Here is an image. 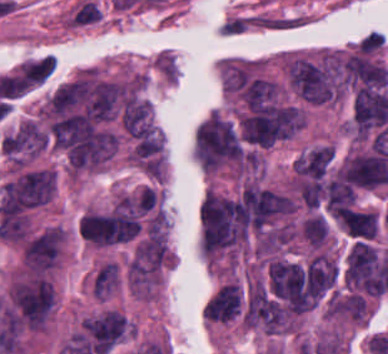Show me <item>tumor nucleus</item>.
<instances>
[{"mask_svg": "<svg viewBox=\"0 0 388 354\" xmlns=\"http://www.w3.org/2000/svg\"><path fill=\"white\" fill-rule=\"evenodd\" d=\"M247 237L238 197L211 192L200 207L201 250L217 255L240 247Z\"/></svg>", "mask_w": 388, "mask_h": 354, "instance_id": "obj_1", "label": "tumor nucleus"}, {"mask_svg": "<svg viewBox=\"0 0 388 354\" xmlns=\"http://www.w3.org/2000/svg\"><path fill=\"white\" fill-rule=\"evenodd\" d=\"M194 154L204 169L214 171L246 158L232 124L215 112L197 126Z\"/></svg>", "mask_w": 388, "mask_h": 354, "instance_id": "obj_2", "label": "tumor nucleus"}, {"mask_svg": "<svg viewBox=\"0 0 388 354\" xmlns=\"http://www.w3.org/2000/svg\"><path fill=\"white\" fill-rule=\"evenodd\" d=\"M12 303L25 324L34 330H42L53 309V286L42 276L17 282L13 288Z\"/></svg>", "mask_w": 388, "mask_h": 354, "instance_id": "obj_3", "label": "tumor nucleus"}, {"mask_svg": "<svg viewBox=\"0 0 388 354\" xmlns=\"http://www.w3.org/2000/svg\"><path fill=\"white\" fill-rule=\"evenodd\" d=\"M293 209L286 193L270 188L247 186L240 198L242 220L250 228L263 230Z\"/></svg>", "mask_w": 388, "mask_h": 354, "instance_id": "obj_4", "label": "tumor nucleus"}, {"mask_svg": "<svg viewBox=\"0 0 388 354\" xmlns=\"http://www.w3.org/2000/svg\"><path fill=\"white\" fill-rule=\"evenodd\" d=\"M127 319L119 312L107 311L86 322L83 329L96 354H107L126 331Z\"/></svg>", "mask_w": 388, "mask_h": 354, "instance_id": "obj_5", "label": "tumor nucleus"}, {"mask_svg": "<svg viewBox=\"0 0 388 354\" xmlns=\"http://www.w3.org/2000/svg\"><path fill=\"white\" fill-rule=\"evenodd\" d=\"M63 239L61 230L48 227L27 241L23 260L32 272H42L54 266Z\"/></svg>", "mask_w": 388, "mask_h": 354, "instance_id": "obj_6", "label": "tumor nucleus"}, {"mask_svg": "<svg viewBox=\"0 0 388 354\" xmlns=\"http://www.w3.org/2000/svg\"><path fill=\"white\" fill-rule=\"evenodd\" d=\"M47 132L30 122H23L1 140L3 153L34 156L44 149Z\"/></svg>", "mask_w": 388, "mask_h": 354, "instance_id": "obj_7", "label": "tumor nucleus"}, {"mask_svg": "<svg viewBox=\"0 0 388 354\" xmlns=\"http://www.w3.org/2000/svg\"><path fill=\"white\" fill-rule=\"evenodd\" d=\"M90 93L88 79H75L58 86L48 104L52 112L63 114L87 99Z\"/></svg>", "mask_w": 388, "mask_h": 354, "instance_id": "obj_8", "label": "tumor nucleus"}, {"mask_svg": "<svg viewBox=\"0 0 388 354\" xmlns=\"http://www.w3.org/2000/svg\"><path fill=\"white\" fill-rule=\"evenodd\" d=\"M242 308V287L215 294L211 297L212 322L228 323L240 317Z\"/></svg>", "mask_w": 388, "mask_h": 354, "instance_id": "obj_9", "label": "tumor nucleus"}, {"mask_svg": "<svg viewBox=\"0 0 388 354\" xmlns=\"http://www.w3.org/2000/svg\"><path fill=\"white\" fill-rule=\"evenodd\" d=\"M355 194L349 184L339 175L326 188V204L328 211L338 213L350 206Z\"/></svg>", "mask_w": 388, "mask_h": 354, "instance_id": "obj_10", "label": "tumor nucleus"}, {"mask_svg": "<svg viewBox=\"0 0 388 354\" xmlns=\"http://www.w3.org/2000/svg\"><path fill=\"white\" fill-rule=\"evenodd\" d=\"M54 69L53 56H46L22 65L19 73L32 85L44 82Z\"/></svg>", "mask_w": 388, "mask_h": 354, "instance_id": "obj_11", "label": "tumor nucleus"}, {"mask_svg": "<svg viewBox=\"0 0 388 354\" xmlns=\"http://www.w3.org/2000/svg\"><path fill=\"white\" fill-rule=\"evenodd\" d=\"M118 286V266L114 262H107L98 270L92 284L93 295L104 297Z\"/></svg>", "mask_w": 388, "mask_h": 354, "instance_id": "obj_12", "label": "tumor nucleus"}, {"mask_svg": "<svg viewBox=\"0 0 388 354\" xmlns=\"http://www.w3.org/2000/svg\"><path fill=\"white\" fill-rule=\"evenodd\" d=\"M303 238L311 247H321L329 230L324 216H316L305 220L301 225Z\"/></svg>", "mask_w": 388, "mask_h": 354, "instance_id": "obj_13", "label": "tumor nucleus"}]
</instances>
